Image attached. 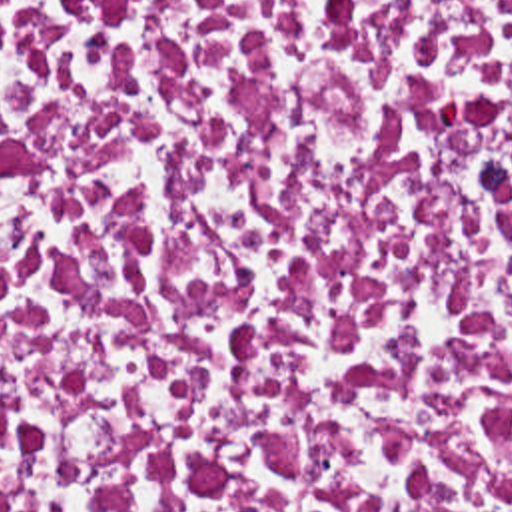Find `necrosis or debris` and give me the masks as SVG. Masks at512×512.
<instances>
[{"label":"necrosis or debris","instance_id":"necrosis-or-debris-1","mask_svg":"<svg viewBox=\"0 0 512 512\" xmlns=\"http://www.w3.org/2000/svg\"><path fill=\"white\" fill-rule=\"evenodd\" d=\"M0 512H512V0H0Z\"/></svg>","mask_w":512,"mask_h":512}]
</instances>
